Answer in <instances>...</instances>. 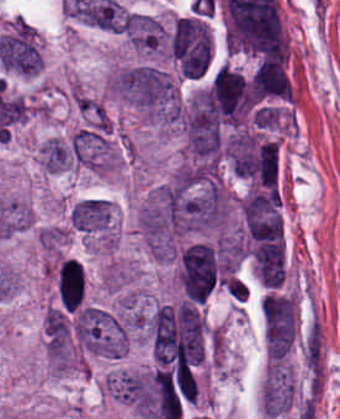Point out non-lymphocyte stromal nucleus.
I'll return each instance as SVG.
<instances>
[{
    "instance_id": "1",
    "label": "non-lymphocyte stromal nucleus",
    "mask_w": 340,
    "mask_h": 419,
    "mask_svg": "<svg viewBox=\"0 0 340 419\" xmlns=\"http://www.w3.org/2000/svg\"><path fill=\"white\" fill-rule=\"evenodd\" d=\"M304 361L309 372L322 373L324 346L322 329L316 320L312 322L303 342Z\"/></svg>"
}]
</instances>
